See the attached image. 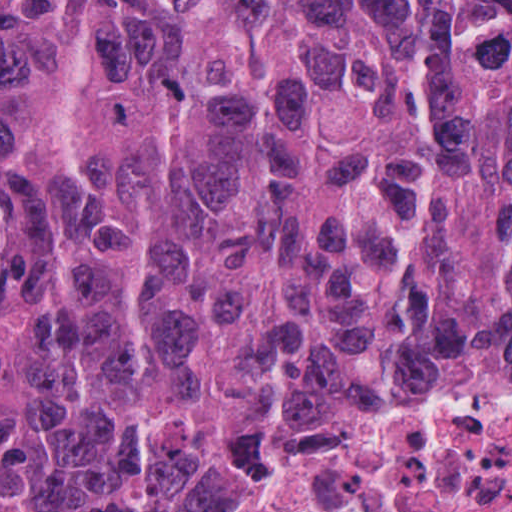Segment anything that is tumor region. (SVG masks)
<instances>
[{
  "label": "tumor region",
  "mask_w": 512,
  "mask_h": 512,
  "mask_svg": "<svg viewBox=\"0 0 512 512\" xmlns=\"http://www.w3.org/2000/svg\"><path fill=\"white\" fill-rule=\"evenodd\" d=\"M430 371L512 372V0H0V512H285Z\"/></svg>",
  "instance_id": "obj_1"
}]
</instances>
